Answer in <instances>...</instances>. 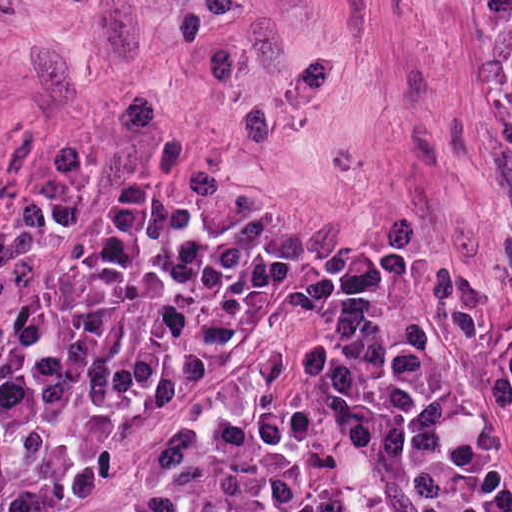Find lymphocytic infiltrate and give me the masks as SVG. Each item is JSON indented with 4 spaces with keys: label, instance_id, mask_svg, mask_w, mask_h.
<instances>
[{
    "label": "lymphocytic infiltrate",
    "instance_id": "f902f5d3",
    "mask_svg": "<svg viewBox=\"0 0 512 512\" xmlns=\"http://www.w3.org/2000/svg\"><path fill=\"white\" fill-rule=\"evenodd\" d=\"M512 133V0H479ZM255 311L357 512H512V328L372 250L236 232L128 188L0 246V512L74 491L155 394ZM98 512H321L292 467L164 445Z\"/></svg>",
    "mask_w": 512,
    "mask_h": 512
}]
</instances>
